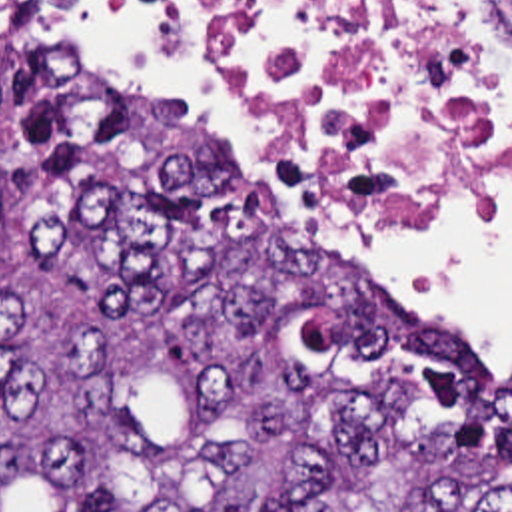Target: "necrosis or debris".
Returning a JSON list of instances; mask_svg holds the SVG:
<instances>
[{
	"label": "necrosis or debris",
	"mask_w": 512,
	"mask_h": 512,
	"mask_svg": "<svg viewBox=\"0 0 512 512\" xmlns=\"http://www.w3.org/2000/svg\"><path fill=\"white\" fill-rule=\"evenodd\" d=\"M246 75L270 117L376 201L504 171L512 0H163Z\"/></svg>",
	"instance_id": "obj_1"
}]
</instances>
